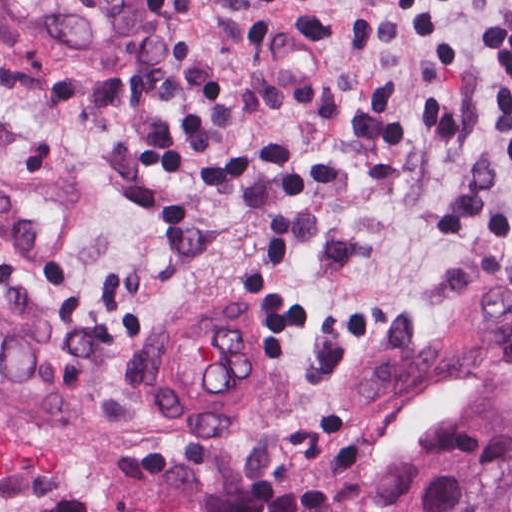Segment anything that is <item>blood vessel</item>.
I'll list each match as a JSON object with an SVG mask.
<instances>
[{
    "label": "blood vessel",
    "instance_id": "obj_1",
    "mask_svg": "<svg viewBox=\"0 0 512 512\" xmlns=\"http://www.w3.org/2000/svg\"><path fill=\"white\" fill-rule=\"evenodd\" d=\"M158 0H0L7 49L35 77L130 76ZM264 317L246 294L206 293L153 334L142 389L154 417L202 439L226 433L260 378Z\"/></svg>",
    "mask_w": 512,
    "mask_h": 512
}]
</instances>
